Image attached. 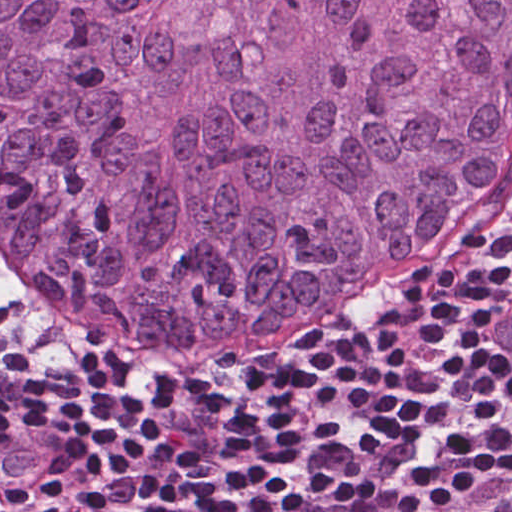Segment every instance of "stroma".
Here are the masks:
<instances>
[{
  "label": "stroma",
  "instance_id": "obj_1",
  "mask_svg": "<svg viewBox=\"0 0 512 512\" xmlns=\"http://www.w3.org/2000/svg\"><path fill=\"white\" fill-rule=\"evenodd\" d=\"M0 307L12 316L24 329L70 362H115L114 359L106 355H99L87 350L74 339L104 354H119L121 351L134 345L121 340L99 339L76 335L47 326L13 307L1 290Z\"/></svg>",
  "mask_w": 512,
  "mask_h": 512
}]
</instances>
